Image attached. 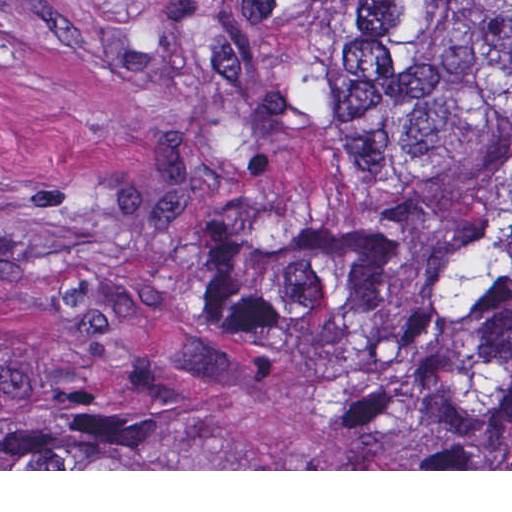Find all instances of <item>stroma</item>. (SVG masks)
<instances>
[{"label": "stroma", "mask_w": 512, "mask_h": 512, "mask_svg": "<svg viewBox=\"0 0 512 512\" xmlns=\"http://www.w3.org/2000/svg\"><path fill=\"white\" fill-rule=\"evenodd\" d=\"M204 1L0 0V392L138 428L130 469L0 471H512V430L425 434L362 367L191 315L253 213Z\"/></svg>", "instance_id": "35a3bbf8"}]
</instances>
